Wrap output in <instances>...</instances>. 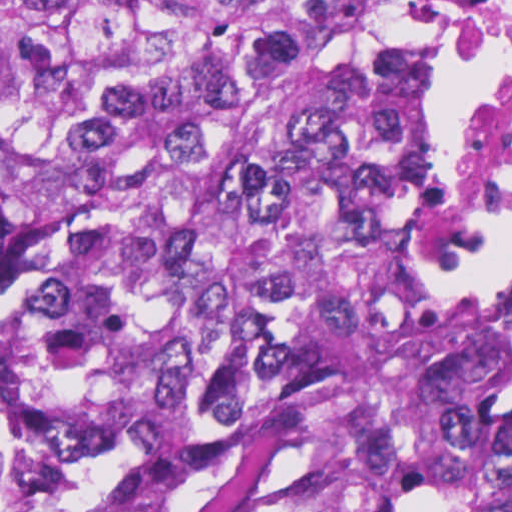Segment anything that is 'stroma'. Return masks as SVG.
Segmentation results:
<instances>
[{"label": "stroma", "instance_id": "1", "mask_svg": "<svg viewBox=\"0 0 512 512\" xmlns=\"http://www.w3.org/2000/svg\"><path fill=\"white\" fill-rule=\"evenodd\" d=\"M497 0H481L443 74L438 149L461 210ZM512 229V207L460 233L454 257L429 293L512 292V272H466L462 264ZM0 243H39L0 217ZM298 308L295 399L262 450L219 487L201 512H333L339 447L333 424L327 341L314 297Z\"/></svg>", "mask_w": 512, "mask_h": 512}]
</instances>
